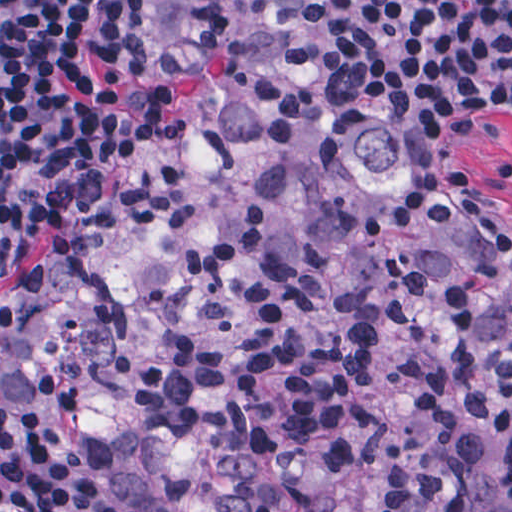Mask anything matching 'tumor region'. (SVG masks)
I'll list each match as a JSON object with an SVG mask.
<instances>
[{
    "instance_id": "1",
    "label": "tumor region",
    "mask_w": 512,
    "mask_h": 512,
    "mask_svg": "<svg viewBox=\"0 0 512 512\" xmlns=\"http://www.w3.org/2000/svg\"><path fill=\"white\" fill-rule=\"evenodd\" d=\"M164 110L0 321L136 512H512V239L339 0H166Z\"/></svg>"
}]
</instances>
